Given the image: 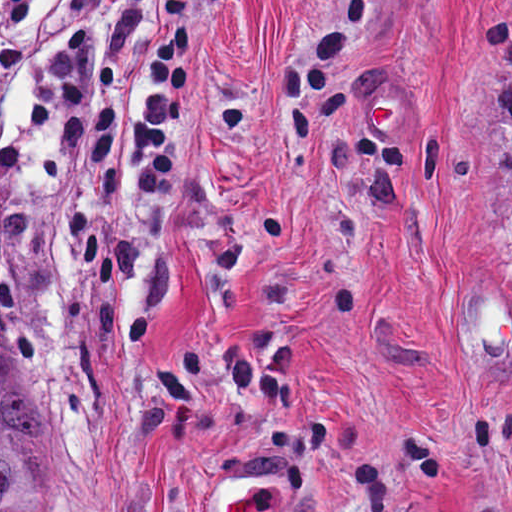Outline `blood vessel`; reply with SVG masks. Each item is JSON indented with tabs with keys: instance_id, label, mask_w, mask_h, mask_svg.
<instances>
[{
	"instance_id": "1",
	"label": "blood vessel",
	"mask_w": 512,
	"mask_h": 512,
	"mask_svg": "<svg viewBox=\"0 0 512 512\" xmlns=\"http://www.w3.org/2000/svg\"><path fill=\"white\" fill-rule=\"evenodd\" d=\"M365 123L378 140H414L419 130V102L389 87H379L365 103Z\"/></svg>"
}]
</instances>
